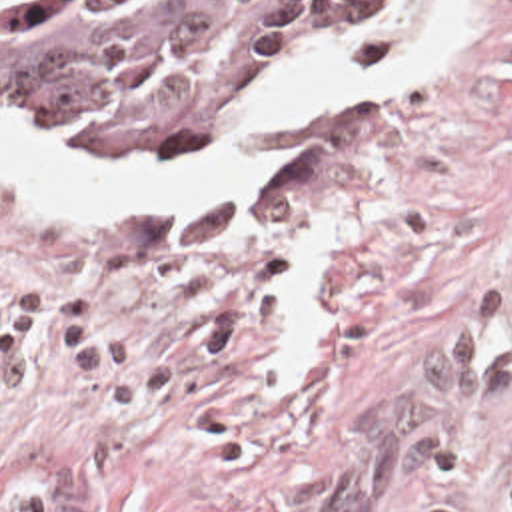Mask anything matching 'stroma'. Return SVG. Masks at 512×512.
<instances>
[{"instance_id": "1", "label": "stroma", "mask_w": 512, "mask_h": 512, "mask_svg": "<svg viewBox=\"0 0 512 512\" xmlns=\"http://www.w3.org/2000/svg\"><path fill=\"white\" fill-rule=\"evenodd\" d=\"M378 7L200 145L76 151L204 149ZM260 137L278 169L188 205L0 173V512H512V0H479L447 65ZM0 139L72 149L4 115ZM310 223L340 255L312 375L282 385Z\"/></svg>"}]
</instances>
